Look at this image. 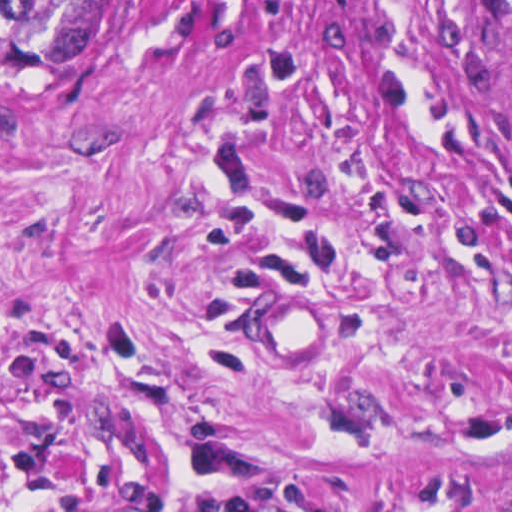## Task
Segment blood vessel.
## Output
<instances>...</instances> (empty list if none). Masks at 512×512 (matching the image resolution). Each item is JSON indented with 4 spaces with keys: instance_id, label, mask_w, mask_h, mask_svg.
Masks as SVG:
<instances>
[{
    "instance_id": "blood-vessel-1",
    "label": "blood vessel",
    "mask_w": 512,
    "mask_h": 512,
    "mask_svg": "<svg viewBox=\"0 0 512 512\" xmlns=\"http://www.w3.org/2000/svg\"><path fill=\"white\" fill-rule=\"evenodd\" d=\"M340 337V302L304 267L250 289L239 309V342L253 365L294 372L327 357Z\"/></svg>"
}]
</instances>
